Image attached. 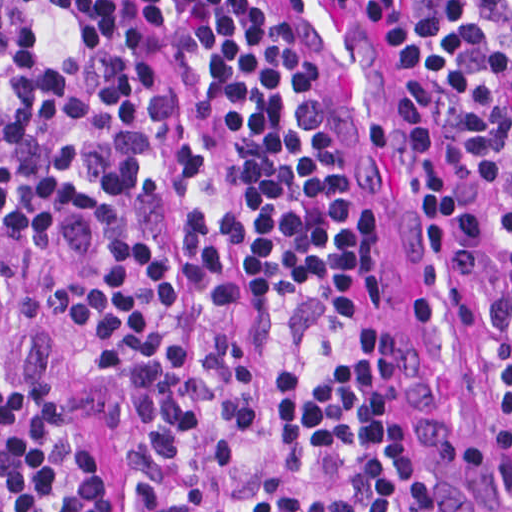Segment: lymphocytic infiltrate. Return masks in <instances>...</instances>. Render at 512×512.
Masks as SVG:
<instances>
[{"mask_svg":"<svg viewBox=\"0 0 512 512\" xmlns=\"http://www.w3.org/2000/svg\"><path fill=\"white\" fill-rule=\"evenodd\" d=\"M438 143L512 400V0H352ZM246 0H0V512H445Z\"/></svg>","mask_w":512,"mask_h":512,"instance_id":"f902f5d3","label":"lymphocytic infiltrate"}]
</instances>
